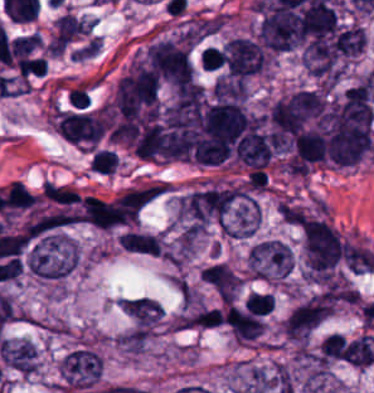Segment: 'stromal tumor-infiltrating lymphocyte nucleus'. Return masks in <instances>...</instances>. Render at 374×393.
Segmentation results:
<instances>
[{
    "label": "stromal tumor-infiltrating lymphocyte nucleus",
    "mask_w": 374,
    "mask_h": 393,
    "mask_svg": "<svg viewBox=\"0 0 374 393\" xmlns=\"http://www.w3.org/2000/svg\"><path fill=\"white\" fill-rule=\"evenodd\" d=\"M47 72L45 57H23L18 59L19 76H39Z\"/></svg>",
    "instance_id": "52c7bb5b"
},
{
    "label": "stromal tumor-infiltrating lymphocyte nucleus",
    "mask_w": 374,
    "mask_h": 393,
    "mask_svg": "<svg viewBox=\"0 0 374 393\" xmlns=\"http://www.w3.org/2000/svg\"><path fill=\"white\" fill-rule=\"evenodd\" d=\"M38 196L23 183L10 182L4 191L6 217L33 206Z\"/></svg>",
    "instance_id": "bc302bb0"
}]
</instances>
